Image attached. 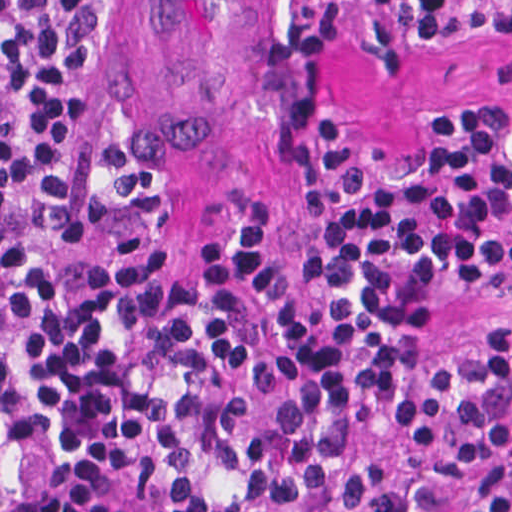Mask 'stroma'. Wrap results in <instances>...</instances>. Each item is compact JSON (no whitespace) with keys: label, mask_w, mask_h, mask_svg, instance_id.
I'll return each instance as SVG.
<instances>
[{"label":"stroma","mask_w":512,"mask_h":512,"mask_svg":"<svg viewBox=\"0 0 512 512\" xmlns=\"http://www.w3.org/2000/svg\"><path fill=\"white\" fill-rule=\"evenodd\" d=\"M251 0H116L109 96L119 145L146 165L149 251L163 282L227 216L259 222L268 261L290 264L318 217L308 155L318 119L341 123L381 156H424L448 119L512 104V43L456 51L414 47L386 11L360 5L327 48L276 34ZM158 287L137 342L136 386L153 356ZM512 317V288L454 297L405 353L453 354L473 321ZM135 386V387H136ZM55 480L70 512H136L130 493L133 396L94 446L19 444Z\"/></svg>","instance_id":"obj_1"}]
</instances>
